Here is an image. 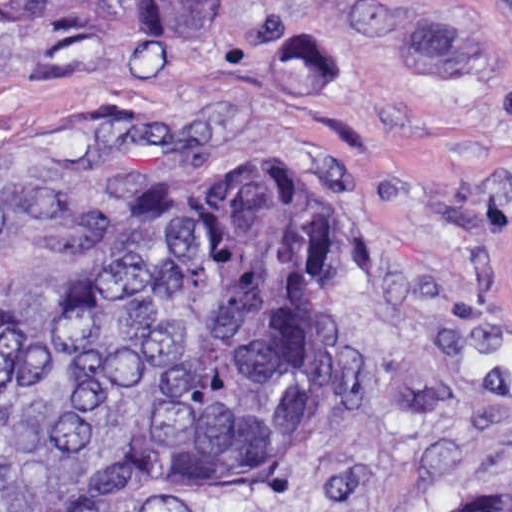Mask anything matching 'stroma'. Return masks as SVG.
Wrapping results in <instances>:
<instances>
[{"instance_id":"35a3bbf8","label":"stroma","mask_w":512,"mask_h":512,"mask_svg":"<svg viewBox=\"0 0 512 512\" xmlns=\"http://www.w3.org/2000/svg\"><path fill=\"white\" fill-rule=\"evenodd\" d=\"M0 105L351 174V414L280 494L185 512H439L512 478V0H223L197 45L0 20Z\"/></svg>"}]
</instances>
